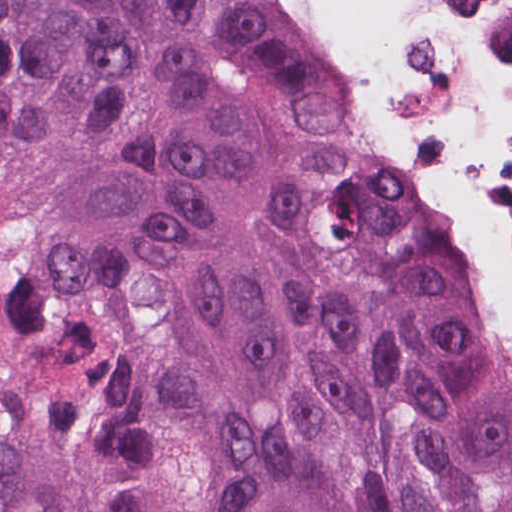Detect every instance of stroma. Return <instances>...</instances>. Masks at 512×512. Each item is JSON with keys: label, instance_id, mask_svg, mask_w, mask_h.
Wrapping results in <instances>:
<instances>
[{"label": "stroma", "instance_id": "35a3bbf8", "mask_svg": "<svg viewBox=\"0 0 512 512\" xmlns=\"http://www.w3.org/2000/svg\"><path fill=\"white\" fill-rule=\"evenodd\" d=\"M277 6L285 14V16L290 20V22L306 35L304 29L302 28V26L298 20V17L295 13V10L293 8L291 1L290 0H277ZM364 102H365L366 111H367L369 117L371 118L372 122L376 126L377 131L380 134V136L382 137L383 141L396 153L387 133L385 132V130L383 129L381 124L377 121L375 114L373 113V111L371 110V108L369 107V105L367 104L365 99H364Z\"/></svg>", "mask_w": 512, "mask_h": 512}]
</instances>
